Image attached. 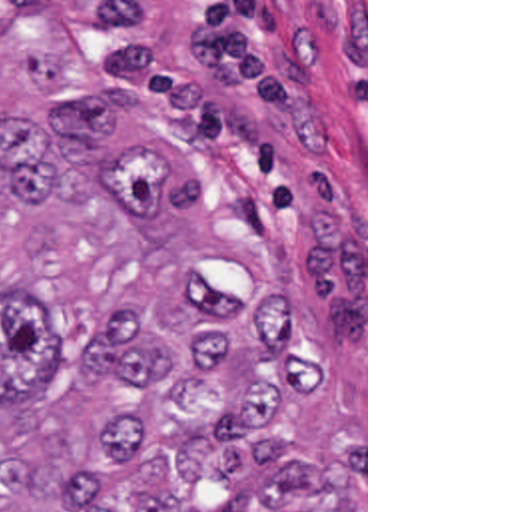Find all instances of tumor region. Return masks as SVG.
I'll use <instances>...</instances> for the list:
<instances>
[{
    "label": "tumor region",
    "instance_id": "tumor-region-1",
    "mask_svg": "<svg viewBox=\"0 0 512 512\" xmlns=\"http://www.w3.org/2000/svg\"><path fill=\"white\" fill-rule=\"evenodd\" d=\"M314 301L0 4V512H364L362 361Z\"/></svg>",
    "mask_w": 512,
    "mask_h": 512
}]
</instances>
